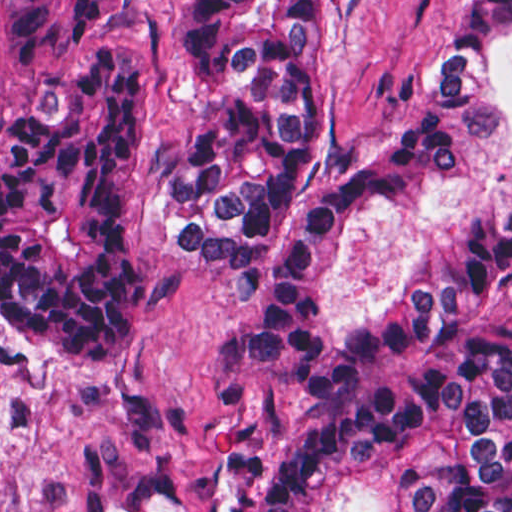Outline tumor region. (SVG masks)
Wrapping results in <instances>:
<instances>
[{
	"label": "tumor region",
	"mask_w": 512,
	"mask_h": 512,
	"mask_svg": "<svg viewBox=\"0 0 512 512\" xmlns=\"http://www.w3.org/2000/svg\"><path fill=\"white\" fill-rule=\"evenodd\" d=\"M141 0H1V318L50 373H112L155 327L139 246L142 59L101 27ZM512 0H449L423 88L380 139L323 123V0H185L204 107L157 213L243 294L271 387L310 381L313 315L363 200L431 209L491 127L481 56ZM257 512H512V184L462 207L410 292L340 345Z\"/></svg>",
	"instance_id": "e687c5a6"
}]
</instances>
